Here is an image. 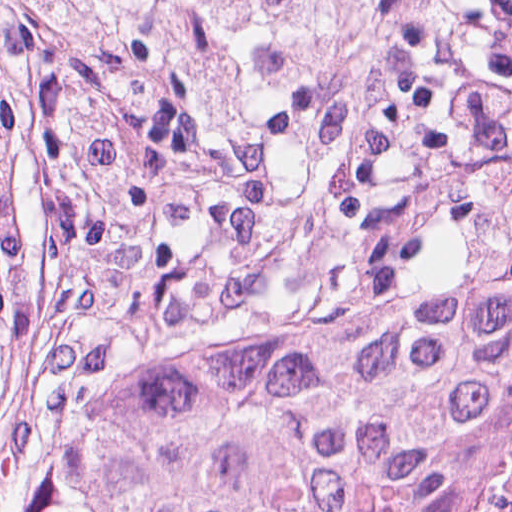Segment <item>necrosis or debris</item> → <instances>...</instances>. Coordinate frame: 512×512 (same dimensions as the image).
<instances>
[{
    "label": "necrosis or debris",
    "instance_id": "1",
    "mask_svg": "<svg viewBox=\"0 0 512 512\" xmlns=\"http://www.w3.org/2000/svg\"><path fill=\"white\" fill-rule=\"evenodd\" d=\"M431 512H512V373L465 423L441 467Z\"/></svg>",
    "mask_w": 512,
    "mask_h": 512
}]
</instances>
